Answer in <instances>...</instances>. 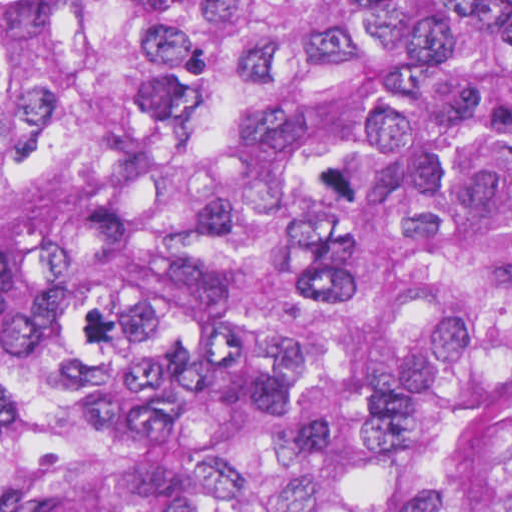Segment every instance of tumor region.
Returning <instances> with one entry per match:
<instances>
[{
	"label": "tumor region",
	"instance_id": "e687c5a6",
	"mask_svg": "<svg viewBox=\"0 0 512 512\" xmlns=\"http://www.w3.org/2000/svg\"><path fill=\"white\" fill-rule=\"evenodd\" d=\"M0 512H512V0H0Z\"/></svg>",
	"mask_w": 512,
	"mask_h": 512
}]
</instances>
